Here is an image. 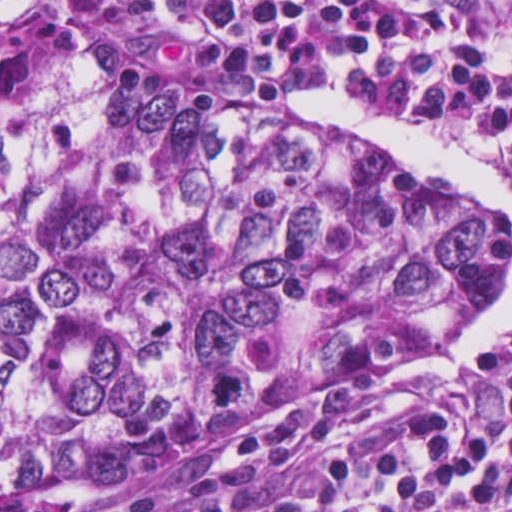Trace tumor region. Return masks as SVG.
I'll list each match as a JSON object with an SVG mask.
<instances>
[{
	"label": "tumor region",
	"instance_id": "1",
	"mask_svg": "<svg viewBox=\"0 0 512 512\" xmlns=\"http://www.w3.org/2000/svg\"><path fill=\"white\" fill-rule=\"evenodd\" d=\"M506 263L507 224L444 182L0 0V502L394 374Z\"/></svg>",
	"mask_w": 512,
	"mask_h": 512
}]
</instances>
